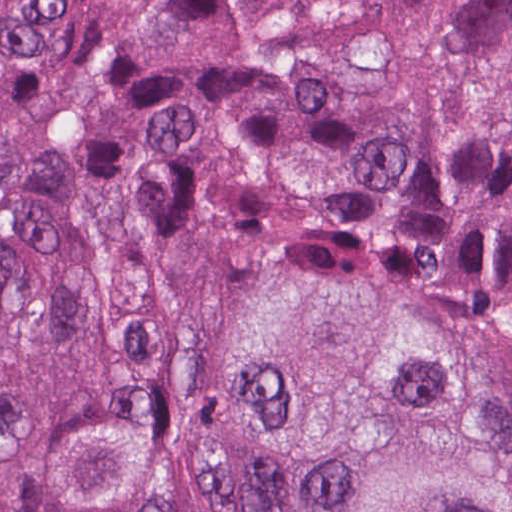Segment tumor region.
<instances>
[{"label": "tumor region", "mask_w": 512, "mask_h": 512, "mask_svg": "<svg viewBox=\"0 0 512 512\" xmlns=\"http://www.w3.org/2000/svg\"><path fill=\"white\" fill-rule=\"evenodd\" d=\"M0 512H512V0H0Z\"/></svg>", "instance_id": "1"}]
</instances>
